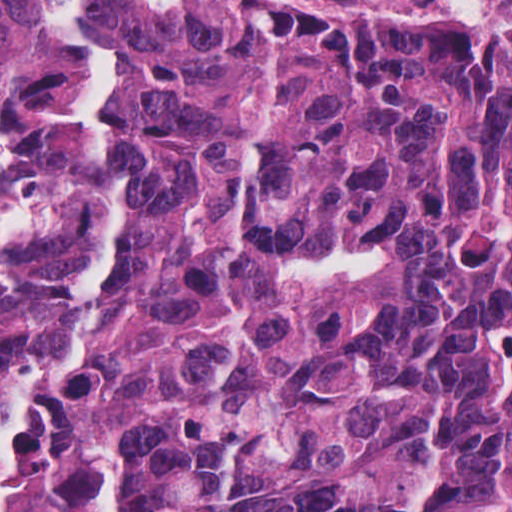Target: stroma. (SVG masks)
<instances>
[{"instance_id":"35a3bbf8","label":"stroma","mask_w":512,"mask_h":512,"mask_svg":"<svg viewBox=\"0 0 512 512\" xmlns=\"http://www.w3.org/2000/svg\"><path fill=\"white\" fill-rule=\"evenodd\" d=\"M98 463L97 512L110 475L123 485V512H152L153 464L142 431L109 410L89 430Z\"/></svg>"}]
</instances>
